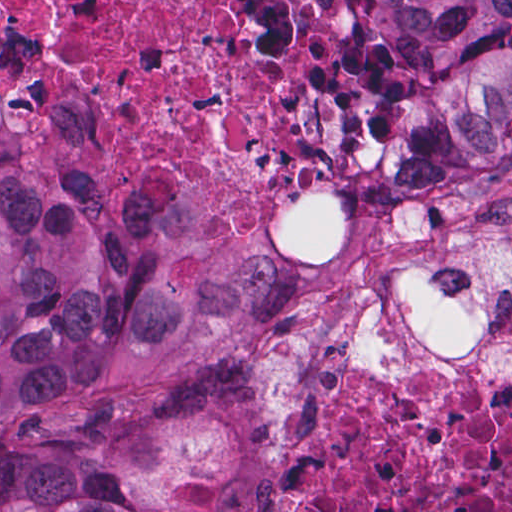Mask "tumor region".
<instances>
[{
    "label": "tumor region",
    "mask_w": 512,
    "mask_h": 512,
    "mask_svg": "<svg viewBox=\"0 0 512 512\" xmlns=\"http://www.w3.org/2000/svg\"><path fill=\"white\" fill-rule=\"evenodd\" d=\"M394 114L374 166L512 158V1H370ZM279 291L95 172L0 43V512H248L241 353Z\"/></svg>",
    "instance_id": "obj_1"
}]
</instances>
